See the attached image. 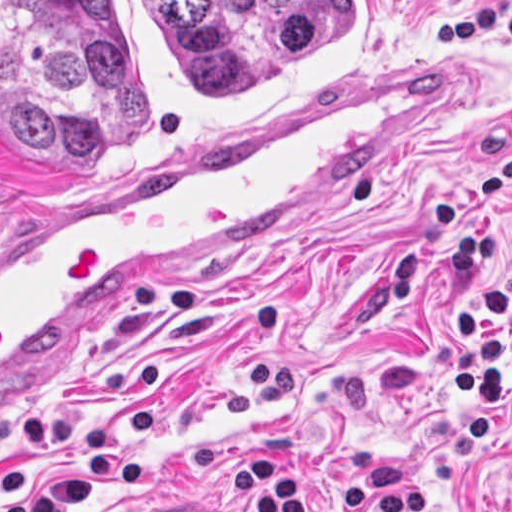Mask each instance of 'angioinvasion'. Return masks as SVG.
<instances>
[{
	"label": "angioinvasion",
	"instance_id": "angioinvasion-1",
	"mask_svg": "<svg viewBox=\"0 0 512 512\" xmlns=\"http://www.w3.org/2000/svg\"><path fill=\"white\" fill-rule=\"evenodd\" d=\"M394 0H1V171L94 181L366 66Z\"/></svg>",
	"mask_w": 512,
	"mask_h": 512
}]
</instances>
